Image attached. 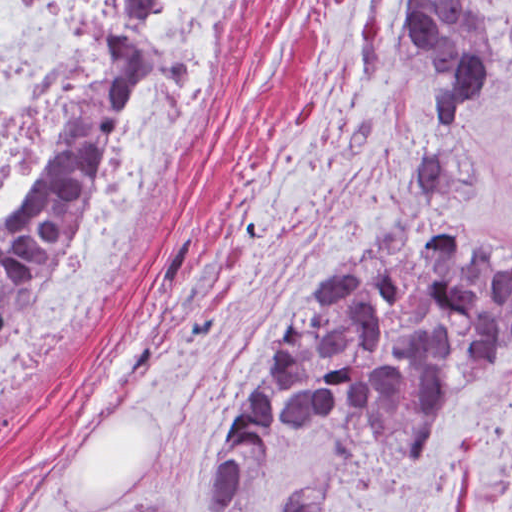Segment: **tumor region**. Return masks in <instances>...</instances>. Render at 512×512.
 <instances>
[{
	"label": "tumor region",
	"mask_w": 512,
	"mask_h": 512,
	"mask_svg": "<svg viewBox=\"0 0 512 512\" xmlns=\"http://www.w3.org/2000/svg\"><path fill=\"white\" fill-rule=\"evenodd\" d=\"M154 12L155 1H118L89 127L0 245V334L145 102ZM387 38L447 131L476 116L507 55V27L484 1H401ZM438 176L431 152L379 227L277 318L230 416L201 512L229 510L280 431L337 425L357 451L377 436L423 446L461 386L512 347V251L494 235L443 228ZM328 491H287L278 509L317 512ZM116 512L184 510L160 495Z\"/></svg>",
	"instance_id": "tumor-region-1"
}]
</instances>
